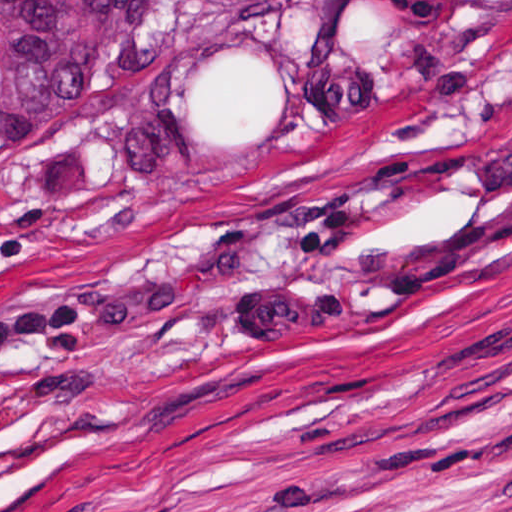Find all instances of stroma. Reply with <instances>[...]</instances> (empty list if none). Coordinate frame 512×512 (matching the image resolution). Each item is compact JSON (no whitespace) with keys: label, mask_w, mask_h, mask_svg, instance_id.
I'll use <instances>...</instances> for the list:
<instances>
[{"label":"stroma","mask_w":512,"mask_h":512,"mask_svg":"<svg viewBox=\"0 0 512 512\" xmlns=\"http://www.w3.org/2000/svg\"><path fill=\"white\" fill-rule=\"evenodd\" d=\"M0 512H512V1L275 156L110 114L22 165Z\"/></svg>","instance_id":"obj_1"}]
</instances>
